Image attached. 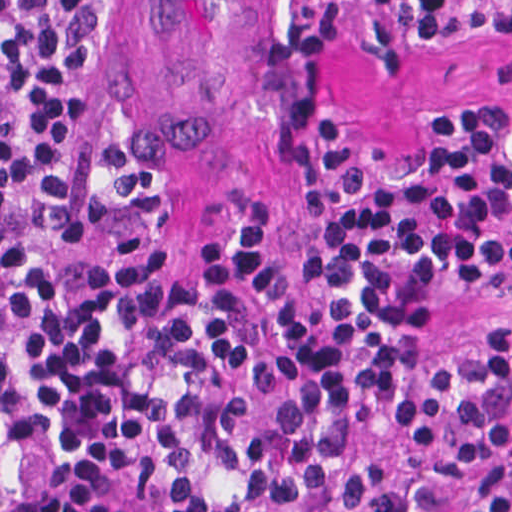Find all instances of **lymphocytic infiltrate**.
Here are the masks:
<instances>
[{
    "label": "lymphocytic infiltrate",
    "mask_w": 512,
    "mask_h": 512,
    "mask_svg": "<svg viewBox=\"0 0 512 512\" xmlns=\"http://www.w3.org/2000/svg\"><path fill=\"white\" fill-rule=\"evenodd\" d=\"M115 2L0 0V426L94 446L133 396L136 512H512V317L405 353L448 300L512 288V104L448 119L413 160L316 120L300 259L268 261L243 213L161 282L146 165L111 112ZM360 5L425 51L512 43V0L250 9L327 48Z\"/></svg>",
    "instance_id": "lymphocytic-infiltrate-1"
}]
</instances>
